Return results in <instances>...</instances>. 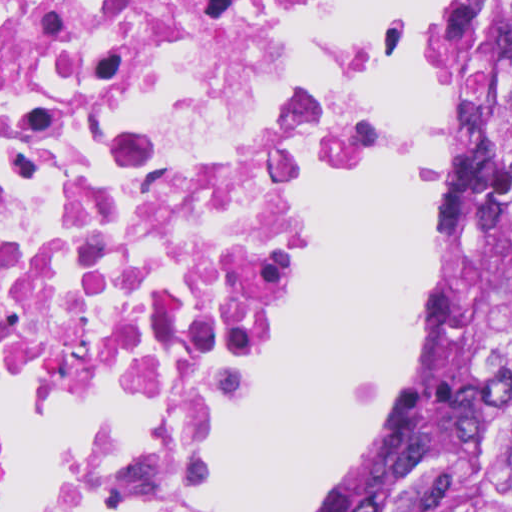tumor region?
Wrapping results in <instances>:
<instances>
[{"instance_id":"tumor-region-1","label":"tumor region","mask_w":512,"mask_h":512,"mask_svg":"<svg viewBox=\"0 0 512 512\" xmlns=\"http://www.w3.org/2000/svg\"><path fill=\"white\" fill-rule=\"evenodd\" d=\"M446 327L430 406L374 512H512V0H439Z\"/></svg>"}]
</instances>
